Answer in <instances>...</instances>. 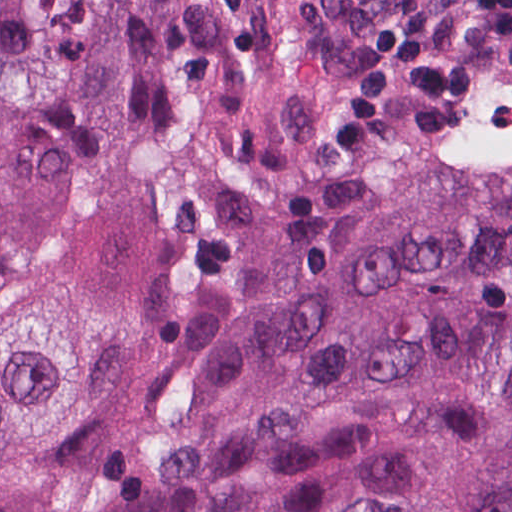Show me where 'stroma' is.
<instances>
[{"label":"stroma","instance_id":"obj_1","mask_svg":"<svg viewBox=\"0 0 512 512\" xmlns=\"http://www.w3.org/2000/svg\"><path fill=\"white\" fill-rule=\"evenodd\" d=\"M393 0H343L330 52V106L352 85L373 29ZM512 39L475 70L459 119L465 137H411L420 104L387 100L367 151L330 156V220H384L436 187L487 177L512 131Z\"/></svg>","mask_w":512,"mask_h":512}]
</instances>
